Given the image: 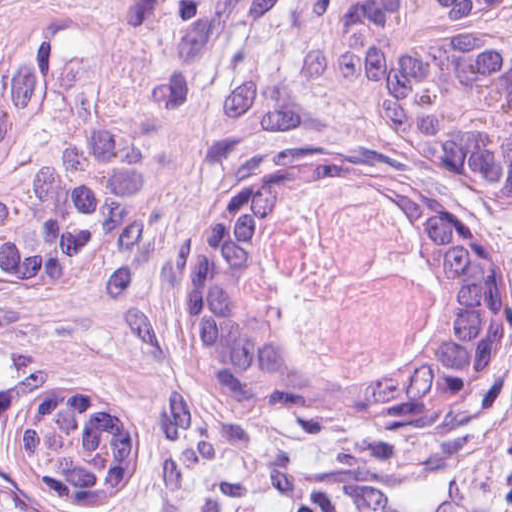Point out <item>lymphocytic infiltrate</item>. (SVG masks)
Returning a JSON list of instances; mask_svg holds the SVG:
<instances>
[{
    "instance_id": "obj_1",
    "label": "lymphocytic infiltrate",
    "mask_w": 512,
    "mask_h": 512,
    "mask_svg": "<svg viewBox=\"0 0 512 512\" xmlns=\"http://www.w3.org/2000/svg\"><path fill=\"white\" fill-rule=\"evenodd\" d=\"M512 38V0H497ZM512 268V230L497 244ZM8 332L0 316V372ZM99 512H512V374L479 421L389 444L237 382L186 387L144 469Z\"/></svg>"
}]
</instances>
